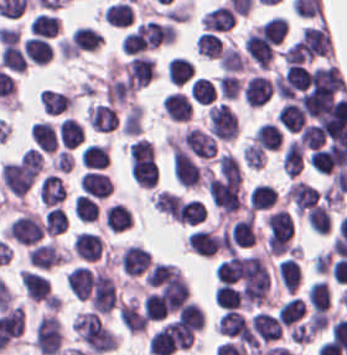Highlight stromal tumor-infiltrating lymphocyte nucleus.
Returning a JSON list of instances; mask_svg holds the SVG:
<instances>
[{"instance_id": "a5eb4a43", "label": "stromal tumor-infiltrating lymphocyte nucleus", "mask_w": 347, "mask_h": 355, "mask_svg": "<svg viewBox=\"0 0 347 355\" xmlns=\"http://www.w3.org/2000/svg\"><path fill=\"white\" fill-rule=\"evenodd\" d=\"M310 227L314 233H328L332 228L329 207L317 205L310 211Z\"/></svg>"}, {"instance_id": "3c572f05", "label": "stromal tumor-infiltrating lymphocyte nucleus", "mask_w": 347, "mask_h": 355, "mask_svg": "<svg viewBox=\"0 0 347 355\" xmlns=\"http://www.w3.org/2000/svg\"><path fill=\"white\" fill-rule=\"evenodd\" d=\"M63 261L64 253L53 241L34 248L28 256V263L49 270L63 264Z\"/></svg>"}, {"instance_id": "023d44f5", "label": "stromal tumor-infiltrating lymphocyte nucleus", "mask_w": 347, "mask_h": 355, "mask_svg": "<svg viewBox=\"0 0 347 355\" xmlns=\"http://www.w3.org/2000/svg\"><path fill=\"white\" fill-rule=\"evenodd\" d=\"M306 313V305L299 295H292L284 301L276 315L282 325L292 326Z\"/></svg>"}, {"instance_id": "42bb06b2", "label": "stromal tumor-infiltrating lymphocyte nucleus", "mask_w": 347, "mask_h": 355, "mask_svg": "<svg viewBox=\"0 0 347 355\" xmlns=\"http://www.w3.org/2000/svg\"><path fill=\"white\" fill-rule=\"evenodd\" d=\"M102 250L101 237L98 233L80 231L73 241V251L80 258L88 262L100 259Z\"/></svg>"}, {"instance_id": "16295066", "label": "stromal tumor-infiltrating lymphocyte nucleus", "mask_w": 347, "mask_h": 355, "mask_svg": "<svg viewBox=\"0 0 347 355\" xmlns=\"http://www.w3.org/2000/svg\"><path fill=\"white\" fill-rule=\"evenodd\" d=\"M2 67L11 72H25L27 57L18 45H4L1 53Z\"/></svg>"}, {"instance_id": "e9af9c67", "label": "stromal tumor-infiltrating lymphocyte nucleus", "mask_w": 347, "mask_h": 355, "mask_svg": "<svg viewBox=\"0 0 347 355\" xmlns=\"http://www.w3.org/2000/svg\"><path fill=\"white\" fill-rule=\"evenodd\" d=\"M229 238L234 247L252 248L254 246L257 234L251 212L234 223Z\"/></svg>"}, {"instance_id": "21d57d70", "label": "stromal tumor-infiltrating lymphocyte nucleus", "mask_w": 347, "mask_h": 355, "mask_svg": "<svg viewBox=\"0 0 347 355\" xmlns=\"http://www.w3.org/2000/svg\"><path fill=\"white\" fill-rule=\"evenodd\" d=\"M254 140L260 148L278 150L283 143V134L275 122H261L254 132Z\"/></svg>"}, {"instance_id": "fc20714e", "label": "stromal tumor-infiltrating lymphocyte nucleus", "mask_w": 347, "mask_h": 355, "mask_svg": "<svg viewBox=\"0 0 347 355\" xmlns=\"http://www.w3.org/2000/svg\"><path fill=\"white\" fill-rule=\"evenodd\" d=\"M220 68L223 72H242L247 62L235 46H228L220 57Z\"/></svg>"}, {"instance_id": "7b516f1d", "label": "stromal tumor-infiltrating lymphocyte nucleus", "mask_w": 347, "mask_h": 355, "mask_svg": "<svg viewBox=\"0 0 347 355\" xmlns=\"http://www.w3.org/2000/svg\"><path fill=\"white\" fill-rule=\"evenodd\" d=\"M249 199L254 210H267L276 203V189L266 183H259Z\"/></svg>"}, {"instance_id": "2761f720", "label": "stromal tumor-infiltrating lymphocyte nucleus", "mask_w": 347, "mask_h": 355, "mask_svg": "<svg viewBox=\"0 0 347 355\" xmlns=\"http://www.w3.org/2000/svg\"><path fill=\"white\" fill-rule=\"evenodd\" d=\"M189 251L200 257H214L221 240L214 230L200 229L193 232L187 241Z\"/></svg>"}, {"instance_id": "04cf8593", "label": "stromal tumor-infiltrating lymphocyte nucleus", "mask_w": 347, "mask_h": 355, "mask_svg": "<svg viewBox=\"0 0 347 355\" xmlns=\"http://www.w3.org/2000/svg\"><path fill=\"white\" fill-rule=\"evenodd\" d=\"M162 106L168 118L177 122H187L191 115V102L188 96L177 91L164 96Z\"/></svg>"}, {"instance_id": "83f04bf1", "label": "stromal tumor-infiltrating lymphocyte nucleus", "mask_w": 347, "mask_h": 355, "mask_svg": "<svg viewBox=\"0 0 347 355\" xmlns=\"http://www.w3.org/2000/svg\"><path fill=\"white\" fill-rule=\"evenodd\" d=\"M198 53L208 58H218L224 48V41L214 31H202L196 41Z\"/></svg>"}, {"instance_id": "8379cbfb", "label": "stromal tumor-infiltrating lymphocyte nucleus", "mask_w": 347, "mask_h": 355, "mask_svg": "<svg viewBox=\"0 0 347 355\" xmlns=\"http://www.w3.org/2000/svg\"><path fill=\"white\" fill-rule=\"evenodd\" d=\"M330 288L328 281L316 279L307 291V301L314 314H322L329 307Z\"/></svg>"}, {"instance_id": "6da75f8f", "label": "stromal tumor-infiltrating lymphocyte nucleus", "mask_w": 347, "mask_h": 355, "mask_svg": "<svg viewBox=\"0 0 347 355\" xmlns=\"http://www.w3.org/2000/svg\"><path fill=\"white\" fill-rule=\"evenodd\" d=\"M216 89L209 78L197 76L191 84L190 96L198 103L210 104L215 97Z\"/></svg>"}, {"instance_id": "4c9ddf68", "label": "stromal tumor-infiltrating lymphocyte nucleus", "mask_w": 347, "mask_h": 355, "mask_svg": "<svg viewBox=\"0 0 347 355\" xmlns=\"http://www.w3.org/2000/svg\"><path fill=\"white\" fill-rule=\"evenodd\" d=\"M86 122L94 129L110 131L117 124V116L112 103L90 102L86 109Z\"/></svg>"}, {"instance_id": "fb6c686a", "label": "stromal tumor-infiltrating lymphocyte nucleus", "mask_w": 347, "mask_h": 355, "mask_svg": "<svg viewBox=\"0 0 347 355\" xmlns=\"http://www.w3.org/2000/svg\"><path fill=\"white\" fill-rule=\"evenodd\" d=\"M67 215L61 207H54L44 216V229L53 236L66 232Z\"/></svg>"}, {"instance_id": "9ea309e8", "label": "stromal tumor-infiltrating lymphocyte nucleus", "mask_w": 347, "mask_h": 355, "mask_svg": "<svg viewBox=\"0 0 347 355\" xmlns=\"http://www.w3.org/2000/svg\"><path fill=\"white\" fill-rule=\"evenodd\" d=\"M19 281L28 301L44 306H55V297L50 284L40 273L21 269Z\"/></svg>"}, {"instance_id": "9e4306bb", "label": "stromal tumor-infiltrating lymphocyte nucleus", "mask_w": 347, "mask_h": 355, "mask_svg": "<svg viewBox=\"0 0 347 355\" xmlns=\"http://www.w3.org/2000/svg\"><path fill=\"white\" fill-rule=\"evenodd\" d=\"M84 193L95 198H105L111 193L112 184L108 175L102 171L88 170L79 181Z\"/></svg>"}, {"instance_id": "ccc9de39", "label": "stromal tumor-infiltrating lymphocyte nucleus", "mask_w": 347, "mask_h": 355, "mask_svg": "<svg viewBox=\"0 0 347 355\" xmlns=\"http://www.w3.org/2000/svg\"><path fill=\"white\" fill-rule=\"evenodd\" d=\"M59 31L60 22L56 15L39 13L32 20L31 34L33 35L53 38Z\"/></svg>"}, {"instance_id": "6c763739", "label": "stromal tumor-infiltrating lymphocyte nucleus", "mask_w": 347, "mask_h": 355, "mask_svg": "<svg viewBox=\"0 0 347 355\" xmlns=\"http://www.w3.org/2000/svg\"><path fill=\"white\" fill-rule=\"evenodd\" d=\"M92 271L79 264L68 273V286L78 299H87L91 291Z\"/></svg>"}, {"instance_id": "4f13568d", "label": "stromal tumor-infiltrating lymphocyte nucleus", "mask_w": 347, "mask_h": 355, "mask_svg": "<svg viewBox=\"0 0 347 355\" xmlns=\"http://www.w3.org/2000/svg\"><path fill=\"white\" fill-rule=\"evenodd\" d=\"M121 68L132 89H139L146 85L157 73L154 61L144 55H137Z\"/></svg>"}, {"instance_id": "84afeb40", "label": "stromal tumor-infiltrating lymphocyte nucleus", "mask_w": 347, "mask_h": 355, "mask_svg": "<svg viewBox=\"0 0 347 355\" xmlns=\"http://www.w3.org/2000/svg\"><path fill=\"white\" fill-rule=\"evenodd\" d=\"M58 137L64 146L76 147L84 141V129L74 117H67L59 123Z\"/></svg>"}, {"instance_id": "894b7857", "label": "stromal tumor-infiltrating lymphocyte nucleus", "mask_w": 347, "mask_h": 355, "mask_svg": "<svg viewBox=\"0 0 347 355\" xmlns=\"http://www.w3.org/2000/svg\"><path fill=\"white\" fill-rule=\"evenodd\" d=\"M74 215L84 222L96 221L98 218V204L90 196L78 195L75 198Z\"/></svg>"}, {"instance_id": "7eef579d", "label": "stromal tumor-infiltrating lymphocyte nucleus", "mask_w": 347, "mask_h": 355, "mask_svg": "<svg viewBox=\"0 0 347 355\" xmlns=\"http://www.w3.org/2000/svg\"><path fill=\"white\" fill-rule=\"evenodd\" d=\"M119 319L126 330L133 333L144 332L148 323L134 298H130L124 302L120 312Z\"/></svg>"}, {"instance_id": "2e467ee5", "label": "stromal tumor-infiltrating lymphocyte nucleus", "mask_w": 347, "mask_h": 355, "mask_svg": "<svg viewBox=\"0 0 347 355\" xmlns=\"http://www.w3.org/2000/svg\"><path fill=\"white\" fill-rule=\"evenodd\" d=\"M39 99L48 114H59L69 110L74 104L72 93L43 88Z\"/></svg>"}, {"instance_id": "abfb95fc", "label": "stromal tumor-infiltrating lymphocyte nucleus", "mask_w": 347, "mask_h": 355, "mask_svg": "<svg viewBox=\"0 0 347 355\" xmlns=\"http://www.w3.org/2000/svg\"><path fill=\"white\" fill-rule=\"evenodd\" d=\"M208 115L210 131L219 139L227 141L239 133L237 114L227 103H214Z\"/></svg>"}, {"instance_id": "57c3b739", "label": "stromal tumor-infiltrating lymphocyte nucleus", "mask_w": 347, "mask_h": 355, "mask_svg": "<svg viewBox=\"0 0 347 355\" xmlns=\"http://www.w3.org/2000/svg\"><path fill=\"white\" fill-rule=\"evenodd\" d=\"M242 81L234 73H224L217 80L221 98L236 99Z\"/></svg>"}, {"instance_id": "52c7bb5b", "label": "stromal tumor-infiltrating lymphocyte nucleus", "mask_w": 347, "mask_h": 355, "mask_svg": "<svg viewBox=\"0 0 347 355\" xmlns=\"http://www.w3.org/2000/svg\"><path fill=\"white\" fill-rule=\"evenodd\" d=\"M62 331L56 314H43L34 332V348L42 355H58Z\"/></svg>"}, {"instance_id": "a33fdf23", "label": "stromal tumor-infiltrating lymphocyte nucleus", "mask_w": 347, "mask_h": 355, "mask_svg": "<svg viewBox=\"0 0 347 355\" xmlns=\"http://www.w3.org/2000/svg\"><path fill=\"white\" fill-rule=\"evenodd\" d=\"M73 33L76 47L80 52L95 50L103 42L102 34L93 27L79 25L75 27Z\"/></svg>"}, {"instance_id": "1d375fb5", "label": "stromal tumor-infiltrating lymphocyte nucleus", "mask_w": 347, "mask_h": 355, "mask_svg": "<svg viewBox=\"0 0 347 355\" xmlns=\"http://www.w3.org/2000/svg\"><path fill=\"white\" fill-rule=\"evenodd\" d=\"M194 63L187 57L174 56L167 67V77L171 83L184 85L194 74Z\"/></svg>"}, {"instance_id": "b6af03f8", "label": "stromal tumor-infiltrating lymphocyte nucleus", "mask_w": 347, "mask_h": 355, "mask_svg": "<svg viewBox=\"0 0 347 355\" xmlns=\"http://www.w3.org/2000/svg\"><path fill=\"white\" fill-rule=\"evenodd\" d=\"M24 56L35 65H44L53 58V49L50 42L38 36H31L26 39L24 45Z\"/></svg>"}, {"instance_id": "18da8d3c", "label": "stromal tumor-infiltrating lymphocyte nucleus", "mask_w": 347, "mask_h": 355, "mask_svg": "<svg viewBox=\"0 0 347 355\" xmlns=\"http://www.w3.org/2000/svg\"><path fill=\"white\" fill-rule=\"evenodd\" d=\"M102 19L110 25L128 26L134 21V10L126 0H119L102 11Z\"/></svg>"}, {"instance_id": "4245b91a", "label": "stromal tumor-infiltrating lymphocyte nucleus", "mask_w": 347, "mask_h": 355, "mask_svg": "<svg viewBox=\"0 0 347 355\" xmlns=\"http://www.w3.org/2000/svg\"><path fill=\"white\" fill-rule=\"evenodd\" d=\"M152 258L144 248L128 245L121 252L119 263L128 277H138L149 269Z\"/></svg>"}, {"instance_id": "fa64b396", "label": "stromal tumor-infiltrating lymphocyte nucleus", "mask_w": 347, "mask_h": 355, "mask_svg": "<svg viewBox=\"0 0 347 355\" xmlns=\"http://www.w3.org/2000/svg\"><path fill=\"white\" fill-rule=\"evenodd\" d=\"M80 161L88 170H101L110 162L107 145L90 143L81 150Z\"/></svg>"}, {"instance_id": "526d6599", "label": "stromal tumor-infiltrating lymphocyte nucleus", "mask_w": 347, "mask_h": 355, "mask_svg": "<svg viewBox=\"0 0 347 355\" xmlns=\"http://www.w3.org/2000/svg\"><path fill=\"white\" fill-rule=\"evenodd\" d=\"M244 163L251 169H261L266 162L265 152L252 140L244 145Z\"/></svg>"}, {"instance_id": "c26a33f6", "label": "stromal tumor-infiltrating lymphocyte nucleus", "mask_w": 347, "mask_h": 355, "mask_svg": "<svg viewBox=\"0 0 347 355\" xmlns=\"http://www.w3.org/2000/svg\"><path fill=\"white\" fill-rule=\"evenodd\" d=\"M244 101L248 107L262 108L271 98V93L254 73L243 86Z\"/></svg>"}, {"instance_id": "50b3126c", "label": "stromal tumor-infiltrating lymphocyte nucleus", "mask_w": 347, "mask_h": 355, "mask_svg": "<svg viewBox=\"0 0 347 355\" xmlns=\"http://www.w3.org/2000/svg\"><path fill=\"white\" fill-rule=\"evenodd\" d=\"M204 220V206L201 201L196 199L182 201L178 222L195 226Z\"/></svg>"}, {"instance_id": "2a367800", "label": "stromal tumor-infiltrating lymphocyte nucleus", "mask_w": 347, "mask_h": 355, "mask_svg": "<svg viewBox=\"0 0 347 355\" xmlns=\"http://www.w3.org/2000/svg\"><path fill=\"white\" fill-rule=\"evenodd\" d=\"M319 196L318 189L302 180H295L285 194L287 201L298 211H311Z\"/></svg>"}, {"instance_id": "02f42fee", "label": "stromal tumor-infiltrating lymphocyte nucleus", "mask_w": 347, "mask_h": 355, "mask_svg": "<svg viewBox=\"0 0 347 355\" xmlns=\"http://www.w3.org/2000/svg\"><path fill=\"white\" fill-rule=\"evenodd\" d=\"M131 223V212L121 202H114L105 212L104 225L112 232H122L131 227Z\"/></svg>"}, {"instance_id": "3e0999b9", "label": "stromal tumor-infiltrating lymphocyte nucleus", "mask_w": 347, "mask_h": 355, "mask_svg": "<svg viewBox=\"0 0 347 355\" xmlns=\"http://www.w3.org/2000/svg\"><path fill=\"white\" fill-rule=\"evenodd\" d=\"M58 133L49 121H35L31 126V138L43 153H54Z\"/></svg>"}, {"instance_id": "afbf053c", "label": "stromal tumor-infiltrating lymphocyte nucleus", "mask_w": 347, "mask_h": 355, "mask_svg": "<svg viewBox=\"0 0 347 355\" xmlns=\"http://www.w3.org/2000/svg\"><path fill=\"white\" fill-rule=\"evenodd\" d=\"M151 203L154 209L169 218L178 221L180 211V195L167 190H159L155 192Z\"/></svg>"}, {"instance_id": "a0a3295f", "label": "stromal tumor-infiltrating lymphocyte nucleus", "mask_w": 347, "mask_h": 355, "mask_svg": "<svg viewBox=\"0 0 347 355\" xmlns=\"http://www.w3.org/2000/svg\"><path fill=\"white\" fill-rule=\"evenodd\" d=\"M276 273L288 293H294L302 279V270L293 257H286L278 264Z\"/></svg>"}, {"instance_id": "782c7336", "label": "stromal tumor-infiltrating lymphocyte nucleus", "mask_w": 347, "mask_h": 355, "mask_svg": "<svg viewBox=\"0 0 347 355\" xmlns=\"http://www.w3.org/2000/svg\"><path fill=\"white\" fill-rule=\"evenodd\" d=\"M39 196L43 206H56L66 197L64 179L53 173L47 175L39 188Z\"/></svg>"}, {"instance_id": "c8d0df70", "label": "stromal tumor-infiltrating lymphocyte nucleus", "mask_w": 347, "mask_h": 355, "mask_svg": "<svg viewBox=\"0 0 347 355\" xmlns=\"http://www.w3.org/2000/svg\"><path fill=\"white\" fill-rule=\"evenodd\" d=\"M219 283H232L239 279L242 266L240 254H231L222 260L216 267Z\"/></svg>"}, {"instance_id": "f3e2335f", "label": "stromal tumor-infiltrating lymphocyte nucleus", "mask_w": 347, "mask_h": 355, "mask_svg": "<svg viewBox=\"0 0 347 355\" xmlns=\"http://www.w3.org/2000/svg\"><path fill=\"white\" fill-rule=\"evenodd\" d=\"M199 158L211 159L216 155V140L213 134L195 127H188L178 140Z\"/></svg>"}, {"instance_id": "4803ca6d", "label": "stromal tumor-infiltrating lymphocyte nucleus", "mask_w": 347, "mask_h": 355, "mask_svg": "<svg viewBox=\"0 0 347 355\" xmlns=\"http://www.w3.org/2000/svg\"><path fill=\"white\" fill-rule=\"evenodd\" d=\"M250 329L257 340L267 344L276 341L282 333L277 316L261 310L251 315Z\"/></svg>"}, {"instance_id": "bc302bb0", "label": "stromal tumor-infiltrating lymphocyte nucleus", "mask_w": 347, "mask_h": 355, "mask_svg": "<svg viewBox=\"0 0 347 355\" xmlns=\"http://www.w3.org/2000/svg\"><path fill=\"white\" fill-rule=\"evenodd\" d=\"M89 303L96 313L110 315L117 306L116 286L110 274L99 267L88 274Z\"/></svg>"}, {"instance_id": "cac63f63", "label": "stromal tumor-infiltrating lymphocyte nucleus", "mask_w": 347, "mask_h": 355, "mask_svg": "<svg viewBox=\"0 0 347 355\" xmlns=\"http://www.w3.org/2000/svg\"><path fill=\"white\" fill-rule=\"evenodd\" d=\"M249 330L244 314L225 310L218 320L217 331L220 335L243 338Z\"/></svg>"}, {"instance_id": "a6e9041d", "label": "stromal tumor-infiltrating lymphocyte nucleus", "mask_w": 347, "mask_h": 355, "mask_svg": "<svg viewBox=\"0 0 347 355\" xmlns=\"http://www.w3.org/2000/svg\"><path fill=\"white\" fill-rule=\"evenodd\" d=\"M177 320L198 332L205 327V313L195 300H188L182 306Z\"/></svg>"}, {"instance_id": "3290ff9b", "label": "stromal tumor-infiltrating lymphocyte nucleus", "mask_w": 347, "mask_h": 355, "mask_svg": "<svg viewBox=\"0 0 347 355\" xmlns=\"http://www.w3.org/2000/svg\"><path fill=\"white\" fill-rule=\"evenodd\" d=\"M6 234L23 247H34L44 235V225L39 215L26 211L9 223Z\"/></svg>"}]
</instances>
